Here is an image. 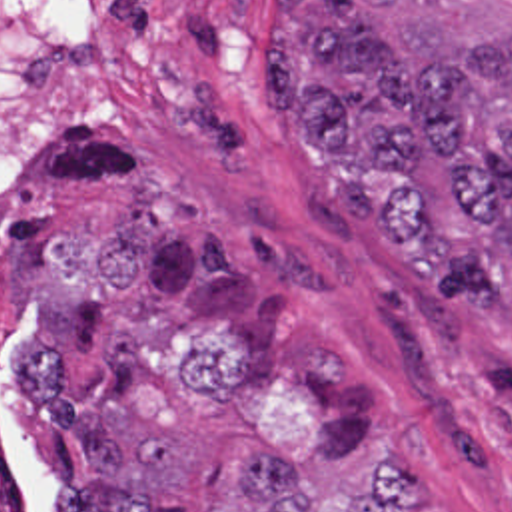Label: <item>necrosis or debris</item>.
I'll return each instance as SVG.
<instances>
[{
	"label": "necrosis or debris",
	"instance_id": "4bbe7bcc",
	"mask_svg": "<svg viewBox=\"0 0 512 512\" xmlns=\"http://www.w3.org/2000/svg\"><path fill=\"white\" fill-rule=\"evenodd\" d=\"M94 42L96 0H0V512H52L14 433L28 343V236L66 152Z\"/></svg>",
	"mask_w": 512,
	"mask_h": 512
}]
</instances>
